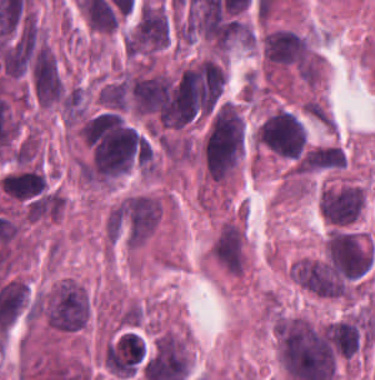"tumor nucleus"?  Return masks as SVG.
<instances>
[{"label":"tumor nucleus","instance_id":"tumor-nucleus-1","mask_svg":"<svg viewBox=\"0 0 375 380\" xmlns=\"http://www.w3.org/2000/svg\"><path fill=\"white\" fill-rule=\"evenodd\" d=\"M247 126L239 105L219 101L210 114L199 146L202 168L214 182L228 183L243 157Z\"/></svg>","mask_w":375,"mask_h":380},{"label":"tumor nucleus","instance_id":"tumor-nucleus-2","mask_svg":"<svg viewBox=\"0 0 375 380\" xmlns=\"http://www.w3.org/2000/svg\"><path fill=\"white\" fill-rule=\"evenodd\" d=\"M161 208L160 200L144 193L125 197L109 211V237L134 250L146 242L154 232Z\"/></svg>","mask_w":375,"mask_h":380},{"label":"tumor nucleus","instance_id":"tumor-nucleus-3","mask_svg":"<svg viewBox=\"0 0 375 380\" xmlns=\"http://www.w3.org/2000/svg\"><path fill=\"white\" fill-rule=\"evenodd\" d=\"M37 310L49 331L75 332L89 318V298L84 286L62 279L37 296Z\"/></svg>","mask_w":375,"mask_h":380},{"label":"tumor nucleus","instance_id":"tumor-nucleus-4","mask_svg":"<svg viewBox=\"0 0 375 380\" xmlns=\"http://www.w3.org/2000/svg\"><path fill=\"white\" fill-rule=\"evenodd\" d=\"M169 12L158 1L142 4L123 36L124 54L138 62H153L169 42Z\"/></svg>","mask_w":375,"mask_h":380},{"label":"tumor nucleus","instance_id":"tumor-nucleus-5","mask_svg":"<svg viewBox=\"0 0 375 380\" xmlns=\"http://www.w3.org/2000/svg\"><path fill=\"white\" fill-rule=\"evenodd\" d=\"M253 137L266 150L293 161L303 152L307 141L306 127L301 116L282 107L264 112Z\"/></svg>","mask_w":375,"mask_h":380},{"label":"tumor nucleus","instance_id":"tumor-nucleus-6","mask_svg":"<svg viewBox=\"0 0 375 380\" xmlns=\"http://www.w3.org/2000/svg\"><path fill=\"white\" fill-rule=\"evenodd\" d=\"M213 260L233 276H244L248 266L246 232L239 220L220 225L211 245Z\"/></svg>","mask_w":375,"mask_h":380},{"label":"tumor nucleus","instance_id":"tumor-nucleus-7","mask_svg":"<svg viewBox=\"0 0 375 380\" xmlns=\"http://www.w3.org/2000/svg\"><path fill=\"white\" fill-rule=\"evenodd\" d=\"M366 204L365 187L343 185L321 191L320 210L323 217L337 224L355 221Z\"/></svg>","mask_w":375,"mask_h":380},{"label":"tumor nucleus","instance_id":"tumor-nucleus-8","mask_svg":"<svg viewBox=\"0 0 375 380\" xmlns=\"http://www.w3.org/2000/svg\"><path fill=\"white\" fill-rule=\"evenodd\" d=\"M345 153L341 146L317 145L308 148L300 160L303 173L332 171L346 166Z\"/></svg>","mask_w":375,"mask_h":380},{"label":"tumor nucleus","instance_id":"tumor-nucleus-9","mask_svg":"<svg viewBox=\"0 0 375 380\" xmlns=\"http://www.w3.org/2000/svg\"><path fill=\"white\" fill-rule=\"evenodd\" d=\"M144 320L143 306L129 302L116 312V324L122 327H137Z\"/></svg>","mask_w":375,"mask_h":380}]
</instances>
